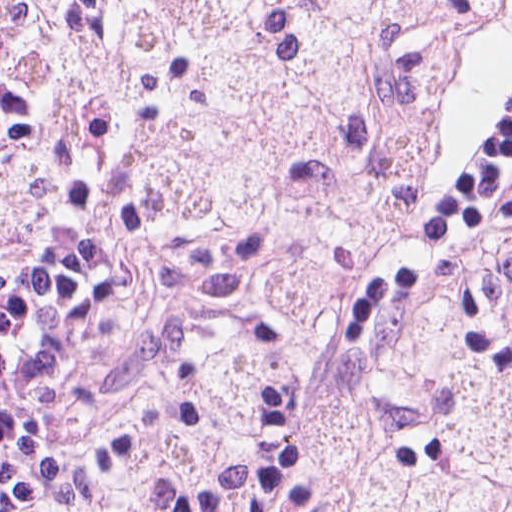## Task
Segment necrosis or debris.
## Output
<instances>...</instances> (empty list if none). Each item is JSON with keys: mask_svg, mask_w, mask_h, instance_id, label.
Wrapping results in <instances>:
<instances>
[{"mask_svg": "<svg viewBox=\"0 0 512 512\" xmlns=\"http://www.w3.org/2000/svg\"><path fill=\"white\" fill-rule=\"evenodd\" d=\"M492 1H69L72 112L212 300L99 445L106 487L512 512V209L404 323L345 333L408 238L447 61Z\"/></svg>", "mask_w": 512, "mask_h": 512, "instance_id": "necrosis-or-debris-1", "label": "necrosis or debris"}]
</instances>
